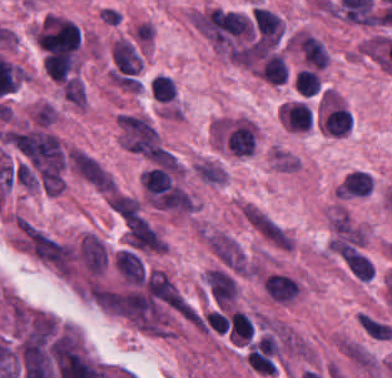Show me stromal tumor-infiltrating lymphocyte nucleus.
<instances>
[{
  "label": "stromal tumor-infiltrating lymphocyte nucleus",
  "instance_id": "f3e2335f",
  "mask_svg": "<svg viewBox=\"0 0 392 378\" xmlns=\"http://www.w3.org/2000/svg\"><path fill=\"white\" fill-rule=\"evenodd\" d=\"M140 184L144 191L157 194L169 188L170 176L164 168L151 167L141 173Z\"/></svg>",
  "mask_w": 392,
  "mask_h": 378
},
{
  "label": "stromal tumor-infiltrating lymphocyte nucleus",
  "instance_id": "52c7bb5b",
  "mask_svg": "<svg viewBox=\"0 0 392 378\" xmlns=\"http://www.w3.org/2000/svg\"><path fill=\"white\" fill-rule=\"evenodd\" d=\"M263 286L278 301H290L299 291L298 282L293 277L274 272L265 277Z\"/></svg>",
  "mask_w": 392,
  "mask_h": 378
},
{
  "label": "stromal tumor-infiltrating lymphocyte nucleus",
  "instance_id": "4245b91a",
  "mask_svg": "<svg viewBox=\"0 0 392 378\" xmlns=\"http://www.w3.org/2000/svg\"><path fill=\"white\" fill-rule=\"evenodd\" d=\"M150 85L153 98L169 102L175 95L172 81L169 78L158 74L152 78Z\"/></svg>",
  "mask_w": 392,
  "mask_h": 378
},
{
  "label": "stromal tumor-infiltrating lymphocyte nucleus",
  "instance_id": "bc302bb0",
  "mask_svg": "<svg viewBox=\"0 0 392 378\" xmlns=\"http://www.w3.org/2000/svg\"><path fill=\"white\" fill-rule=\"evenodd\" d=\"M223 139L227 150L235 157H246L254 152V130L246 122H233L226 128Z\"/></svg>",
  "mask_w": 392,
  "mask_h": 378
},
{
  "label": "stromal tumor-infiltrating lymphocyte nucleus",
  "instance_id": "2a367800",
  "mask_svg": "<svg viewBox=\"0 0 392 378\" xmlns=\"http://www.w3.org/2000/svg\"><path fill=\"white\" fill-rule=\"evenodd\" d=\"M259 73L272 84H280L286 79V66L279 56L269 54Z\"/></svg>",
  "mask_w": 392,
  "mask_h": 378
},
{
  "label": "stromal tumor-infiltrating lymphocyte nucleus",
  "instance_id": "3290ff9b",
  "mask_svg": "<svg viewBox=\"0 0 392 378\" xmlns=\"http://www.w3.org/2000/svg\"><path fill=\"white\" fill-rule=\"evenodd\" d=\"M338 191L343 196H367L370 191V177L359 171L348 172Z\"/></svg>",
  "mask_w": 392,
  "mask_h": 378
},
{
  "label": "stromal tumor-infiltrating lymphocyte nucleus",
  "instance_id": "4f13568d",
  "mask_svg": "<svg viewBox=\"0 0 392 378\" xmlns=\"http://www.w3.org/2000/svg\"><path fill=\"white\" fill-rule=\"evenodd\" d=\"M253 325L247 315L233 311L228 321L229 338L232 342H245L250 336Z\"/></svg>",
  "mask_w": 392,
  "mask_h": 378
},
{
  "label": "stromal tumor-infiltrating lymphocyte nucleus",
  "instance_id": "4803ca6d",
  "mask_svg": "<svg viewBox=\"0 0 392 378\" xmlns=\"http://www.w3.org/2000/svg\"><path fill=\"white\" fill-rule=\"evenodd\" d=\"M293 84L304 95H311L318 90L319 83L313 71L299 69L294 76Z\"/></svg>",
  "mask_w": 392,
  "mask_h": 378
},
{
  "label": "stromal tumor-infiltrating lymphocyte nucleus",
  "instance_id": "9ea309e8",
  "mask_svg": "<svg viewBox=\"0 0 392 378\" xmlns=\"http://www.w3.org/2000/svg\"><path fill=\"white\" fill-rule=\"evenodd\" d=\"M299 47L305 64L324 68L326 53L315 37L305 35L301 38Z\"/></svg>",
  "mask_w": 392,
  "mask_h": 378
},
{
  "label": "stromal tumor-infiltrating lymphocyte nucleus",
  "instance_id": "abfb95fc",
  "mask_svg": "<svg viewBox=\"0 0 392 378\" xmlns=\"http://www.w3.org/2000/svg\"><path fill=\"white\" fill-rule=\"evenodd\" d=\"M352 123L347 108L334 107L323 119L324 131L333 136H343Z\"/></svg>",
  "mask_w": 392,
  "mask_h": 378
}]
</instances>
